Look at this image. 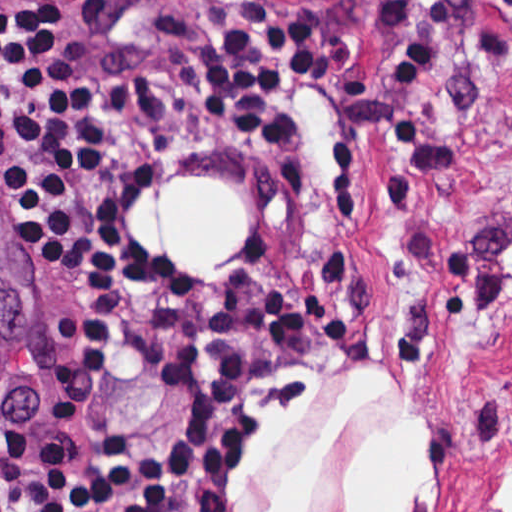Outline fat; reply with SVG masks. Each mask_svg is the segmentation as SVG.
Instances as JSON below:
<instances>
[{"mask_svg": "<svg viewBox=\"0 0 512 512\" xmlns=\"http://www.w3.org/2000/svg\"><path fill=\"white\" fill-rule=\"evenodd\" d=\"M123 231L199 287L236 276L235 259L250 242V194L225 176L156 177L140 184L120 209ZM379 391L368 381L340 399L335 421L285 477L278 502L264 512H296L302 484L341 415ZM419 429L402 426L369 439L356 455L346 512H402L430 465Z\"/></svg>", "mask_w": 512, "mask_h": 512, "instance_id": "fat-1", "label": "fat"}]
</instances>
